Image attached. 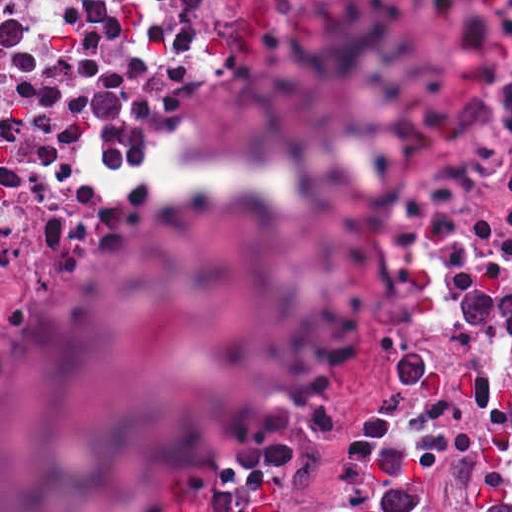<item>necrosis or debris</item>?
I'll list each match as a JSON object with an SVG mask.
<instances>
[{
    "instance_id": "4bbe7bcc",
    "label": "necrosis or debris",
    "mask_w": 512,
    "mask_h": 512,
    "mask_svg": "<svg viewBox=\"0 0 512 512\" xmlns=\"http://www.w3.org/2000/svg\"><path fill=\"white\" fill-rule=\"evenodd\" d=\"M46 0H0V21L36 6Z\"/></svg>"
}]
</instances>
